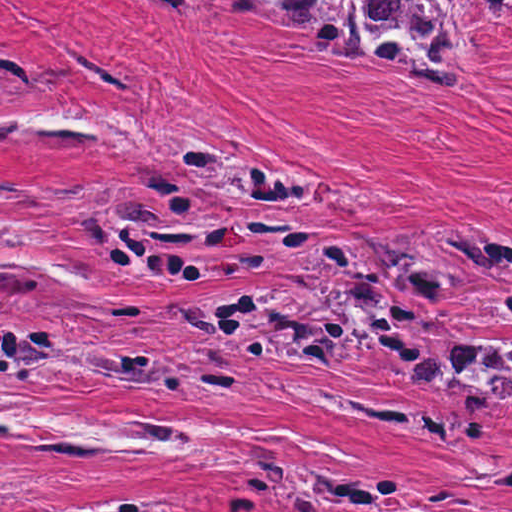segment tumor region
<instances>
[{
	"label": "tumor region",
	"mask_w": 512,
	"mask_h": 512,
	"mask_svg": "<svg viewBox=\"0 0 512 512\" xmlns=\"http://www.w3.org/2000/svg\"><path fill=\"white\" fill-rule=\"evenodd\" d=\"M175 23L201 14L208 0H151ZM240 20H272L333 61L392 71L420 98H436L460 80V51L445 0H223ZM512 31V0H485ZM38 65L1 47V92L35 91ZM154 158L134 169L130 185L75 228L87 263L105 262L143 284L240 276L287 262L311 226L277 223L262 211H230L209 192L289 208L311 193V176L277 162H247L158 134ZM291 271V285H268L217 298L167 304L189 325L225 346L186 348L171 364L142 344L92 339L80 353L82 377L125 380L178 399L232 406L247 374L230 346L292 359L341 375V365L385 357L394 377L423 383L457 400L512 406V250L498 252L478 224L323 244ZM1 264H15L1 255ZM24 333L21 358L1 377L41 379L48 342ZM347 369V370H348ZM225 436H273L266 429H214L1 407V446H32L88 455L178 457L225 463L207 444ZM252 455L259 480L236 492L278 499L300 512H512L463 496L457 488L404 486L387 474L348 468L293 469L267 444ZM172 496L142 493L42 512H165Z\"/></svg>",
	"instance_id": "tumor-region-1"
}]
</instances>
